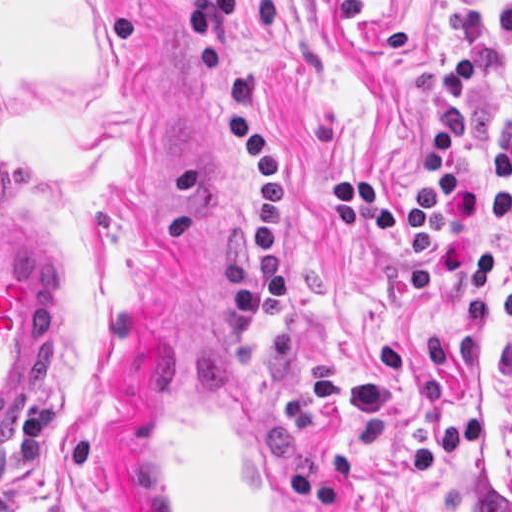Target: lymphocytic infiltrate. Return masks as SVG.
Here are the masks:
<instances>
[{"instance_id": "lymphocytic-infiltrate-1", "label": "lymphocytic infiltrate", "mask_w": 512, "mask_h": 512, "mask_svg": "<svg viewBox=\"0 0 512 512\" xmlns=\"http://www.w3.org/2000/svg\"><path fill=\"white\" fill-rule=\"evenodd\" d=\"M191 4L210 115L229 164L247 186L244 269L266 304L276 339H284L297 328L293 177L283 153L260 138L234 104L227 77L233 0ZM462 28L468 52L432 76L417 203L410 209L376 174L352 172L328 186L326 222L349 236L389 238L402 256L409 293L423 309L451 277L464 303V325L486 327L502 244L477 234L512 222V118L480 176L471 177L465 157L477 136V108L465 102L512 49V0H496L494 34L473 5L464 7Z\"/></svg>"}]
</instances>
